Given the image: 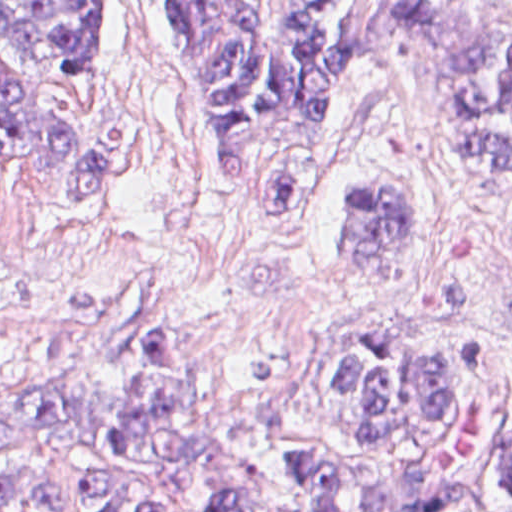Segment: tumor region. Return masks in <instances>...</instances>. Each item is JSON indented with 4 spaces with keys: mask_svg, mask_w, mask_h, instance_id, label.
Segmentation results:
<instances>
[{
    "mask_svg": "<svg viewBox=\"0 0 512 512\" xmlns=\"http://www.w3.org/2000/svg\"><path fill=\"white\" fill-rule=\"evenodd\" d=\"M116 0H0V43L73 77ZM187 78L210 149L248 217L306 228L331 184L339 101L378 65L439 120L438 164L512 182V0H361L354 22L314 0H141ZM77 73L71 74L59 68ZM0 168L39 202L98 208V160L45 86L0 62ZM340 208L352 257H406L414 208L388 177ZM316 374L260 416L197 398L181 330L137 338L123 389L23 403L8 429L100 453L65 488L0 474V512H512V402L502 344L421 314L366 318L313 344Z\"/></svg>",
    "mask_w": 512,
    "mask_h": 512,
    "instance_id": "e687c5a6",
    "label": "tumor region"
}]
</instances>
